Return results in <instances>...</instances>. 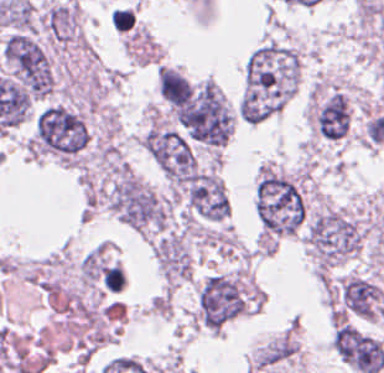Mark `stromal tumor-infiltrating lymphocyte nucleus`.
<instances>
[{
  "label": "stromal tumor-infiltrating lymphocyte nucleus",
  "instance_id": "stromal-tumor-infiltrating-lymphocyte-nucleus-1",
  "mask_svg": "<svg viewBox=\"0 0 384 373\" xmlns=\"http://www.w3.org/2000/svg\"><path fill=\"white\" fill-rule=\"evenodd\" d=\"M124 281V272L118 264L106 265L103 270V284L107 290H120Z\"/></svg>",
  "mask_w": 384,
  "mask_h": 373
}]
</instances>
